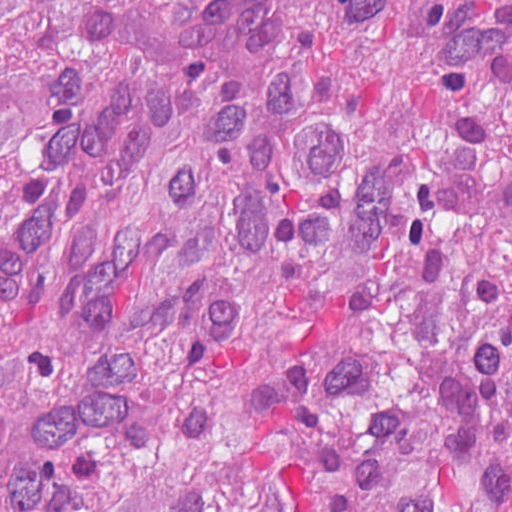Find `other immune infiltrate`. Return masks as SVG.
I'll list each match as a JSON object with an SVG mask.
<instances>
[{
    "label": "other immune infiltrate",
    "instance_id": "1",
    "mask_svg": "<svg viewBox=\"0 0 512 512\" xmlns=\"http://www.w3.org/2000/svg\"><path fill=\"white\" fill-rule=\"evenodd\" d=\"M182 54L195 66L211 67V3L193 14L176 35Z\"/></svg>",
    "mask_w": 512,
    "mask_h": 512
}]
</instances>
